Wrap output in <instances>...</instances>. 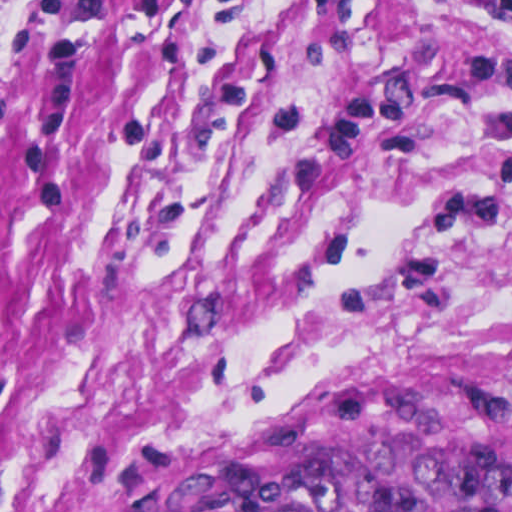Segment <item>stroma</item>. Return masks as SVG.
<instances>
[{
  "mask_svg": "<svg viewBox=\"0 0 512 512\" xmlns=\"http://www.w3.org/2000/svg\"><path fill=\"white\" fill-rule=\"evenodd\" d=\"M512 386V18L0 0V512H147L272 412Z\"/></svg>",
  "mask_w": 512,
  "mask_h": 512,
  "instance_id": "35a3bbf8",
  "label": "stroma"
}]
</instances>
